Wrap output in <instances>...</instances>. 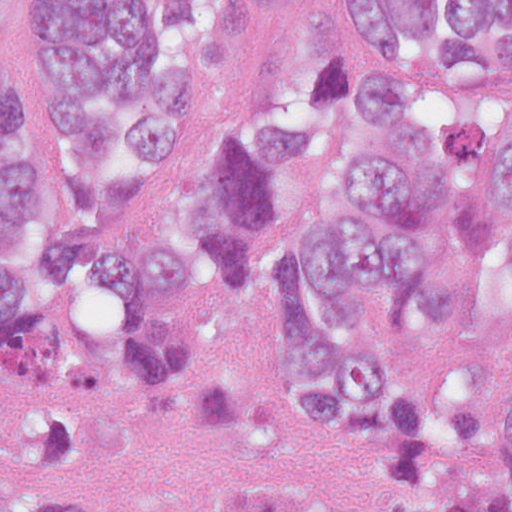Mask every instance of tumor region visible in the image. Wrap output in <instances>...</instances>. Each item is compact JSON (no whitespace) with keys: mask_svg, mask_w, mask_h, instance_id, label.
I'll return each instance as SVG.
<instances>
[{"mask_svg":"<svg viewBox=\"0 0 512 512\" xmlns=\"http://www.w3.org/2000/svg\"><path fill=\"white\" fill-rule=\"evenodd\" d=\"M0 0V446L92 450L115 416L250 431L262 390L168 324L213 279L290 281L285 400H389L356 485L194 489L172 512H512V137L466 83L512 71V0H32L46 111ZM117 295L142 323L47 311ZM0 512H84L47 485Z\"/></svg>","mask_w":512,"mask_h":512,"instance_id":"e687c5a6","label":"tumor region"}]
</instances>
